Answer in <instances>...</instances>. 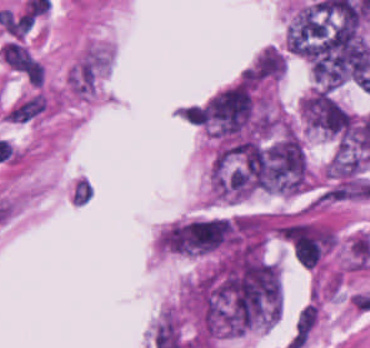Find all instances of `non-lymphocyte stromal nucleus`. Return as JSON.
Here are the masks:
<instances>
[{"instance_id": "obj_1", "label": "non-lymphocyte stromal nucleus", "mask_w": 370, "mask_h": 348, "mask_svg": "<svg viewBox=\"0 0 370 348\" xmlns=\"http://www.w3.org/2000/svg\"><path fill=\"white\" fill-rule=\"evenodd\" d=\"M113 58V44L100 39L86 41L66 70L68 96L87 104L98 99L113 67Z\"/></svg>"}, {"instance_id": "obj_2", "label": "non-lymphocyte stromal nucleus", "mask_w": 370, "mask_h": 348, "mask_svg": "<svg viewBox=\"0 0 370 348\" xmlns=\"http://www.w3.org/2000/svg\"><path fill=\"white\" fill-rule=\"evenodd\" d=\"M49 102L46 93L35 90L19 98L10 109V120L29 121L42 114Z\"/></svg>"}]
</instances>
